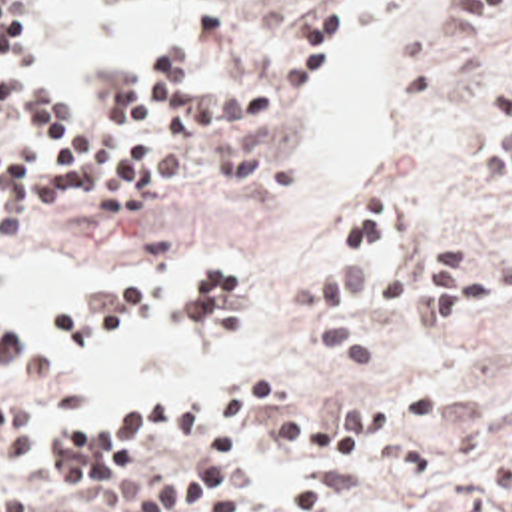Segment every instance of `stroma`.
<instances>
[{"label": "stroma", "mask_w": 512, "mask_h": 512, "mask_svg": "<svg viewBox=\"0 0 512 512\" xmlns=\"http://www.w3.org/2000/svg\"><path fill=\"white\" fill-rule=\"evenodd\" d=\"M191 1H205L209 13L219 3L227 33L191 65L187 87H215L239 75L285 23L317 3L331 7V51L339 33L337 0H101V7L117 17H135ZM51 11L45 9L41 29ZM509 47L512 31L491 47L463 45L455 31V0H415L399 101L389 117V148L353 176L321 178L301 146L315 101L311 87L261 144L241 154L193 158L157 190L137 228L107 232L83 218L79 206H59L17 242L67 246L105 262H183L187 268L193 260H223L239 276V314L191 350L197 358L213 354L219 338L251 332L257 316L275 322L277 372L265 380L261 420L387 398L409 384L441 388V418L415 430L439 460L437 484L411 486L389 472L351 470L295 450L265 448L255 426L243 450L231 512H512V302L427 336L409 314L359 298L349 316L375 340V366L365 372H335L313 346L311 322L281 308L283 282L319 270L329 220L367 178L395 182L407 200L405 224L375 262V278L387 282L435 240L465 242L485 264L512 256V192L499 194L479 172L481 141L499 111L493 81ZM21 65L35 71L29 59ZM125 286L147 292L173 288ZM243 392L223 406L191 400L189 426L137 442L135 456L165 464L199 462L209 436ZM1 398L43 400L39 452L9 474L11 488L31 510L113 512L75 494L83 490L61 474L59 426L137 402L51 410V378L43 364L35 384L0 386Z\"/></svg>", "instance_id": "obj_1"}]
</instances>
